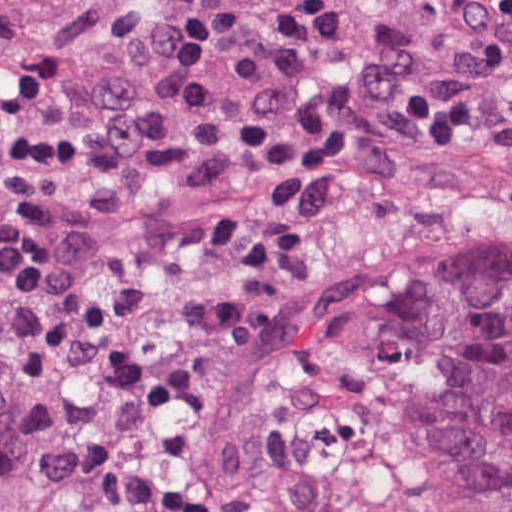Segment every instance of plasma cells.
I'll use <instances>...</instances> for the list:
<instances>
[{"mask_svg": "<svg viewBox=\"0 0 512 512\" xmlns=\"http://www.w3.org/2000/svg\"><path fill=\"white\" fill-rule=\"evenodd\" d=\"M251 3L127 21L19 80L0 105V385L18 418L11 451L76 497L114 490L190 432L304 291L310 234L298 216L221 212L185 261L169 320L121 384L78 382V362L131 320L144 293L84 273L65 181L83 173L191 188L239 167L278 128L235 101L228 69L334 48L353 17L350 0Z\"/></svg>", "mask_w": 512, "mask_h": 512, "instance_id": "obj_1", "label": "plasma cells"}]
</instances>
